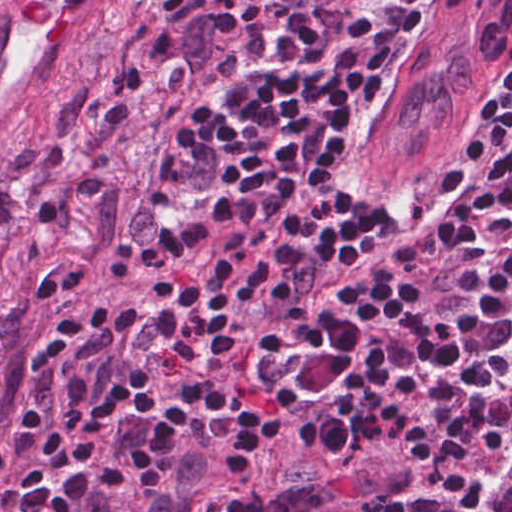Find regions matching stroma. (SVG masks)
<instances>
[{"label": "stroma", "instance_id": "stroma-1", "mask_svg": "<svg viewBox=\"0 0 512 512\" xmlns=\"http://www.w3.org/2000/svg\"><path fill=\"white\" fill-rule=\"evenodd\" d=\"M512 61L440 139L385 201L424 212L445 201L453 188L458 157L470 140V128L489 94L504 80Z\"/></svg>", "mask_w": 512, "mask_h": 512}]
</instances>
